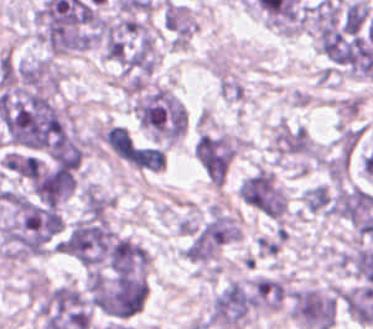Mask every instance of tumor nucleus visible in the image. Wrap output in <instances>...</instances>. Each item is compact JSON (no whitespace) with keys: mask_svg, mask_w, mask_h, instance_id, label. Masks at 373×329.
Returning a JSON list of instances; mask_svg holds the SVG:
<instances>
[{"mask_svg":"<svg viewBox=\"0 0 373 329\" xmlns=\"http://www.w3.org/2000/svg\"><path fill=\"white\" fill-rule=\"evenodd\" d=\"M232 238V217L224 211L211 210L186 230L183 258L197 264H211Z\"/></svg>","mask_w":373,"mask_h":329,"instance_id":"1","label":"tumor nucleus"},{"mask_svg":"<svg viewBox=\"0 0 373 329\" xmlns=\"http://www.w3.org/2000/svg\"><path fill=\"white\" fill-rule=\"evenodd\" d=\"M358 140V131L342 126L324 161L326 175L332 182H341L345 176Z\"/></svg>","mask_w":373,"mask_h":329,"instance_id":"2","label":"tumor nucleus"},{"mask_svg":"<svg viewBox=\"0 0 373 329\" xmlns=\"http://www.w3.org/2000/svg\"><path fill=\"white\" fill-rule=\"evenodd\" d=\"M273 151L278 156H312L313 143L302 126L278 123L272 132Z\"/></svg>","mask_w":373,"mask_h":329,"instance_id":"3","label":"tumor nucleus"},{"mask_svg":"<svg viewBox=\"0 0 373 329\" xmlns=\"http://www.w3.org/2000/svg\"><path fill=\"white\" fill-rule=\"evenodd\" d=\"M254 305L259 309L279 306L286 292L284 282L269 276H255L249 280Z\"/></svg>","mask_w":373,"mask_h":329,"instance_id":"4","label":"tumor nucleus"},{"mask_svg":"<svg viewBox=\"0 0 373 329\" xmlns=\"http://www.w3.org/2000/svg\"><path fill=\"white\" fill-rule=\"evenodd\" d=\"M111 205V197L93 184L82 188V210L89 216H105Z\"/></svg>","mask_w":373,"mask_h":329,"instance_id":"5","label":"tumor nucleus"},{"mask_svg":"<svg viewBox=\"0 0 373 329\" xmlns=\"http://www.w3.org/2000/svg\"><path fill=\"white\" fill-rule=\"evenodd\" d=\"M301 197L304 207L312 212L328 215L332 200L327 186L322 184L307 186Z\"/></svg>","mask_w":373,"mask_h":329,"instance_id":"6","label":"tumor nucleus"},{"mask_svg":"<svg viewBox=\"0 0 373 329\" xmlns=\"http://www.w3.org/2000/svg\"><path fill=\"white\" fill-rule=\"evenodd\" d=\"M281 242L274 236H260L254 248L260 256H274L280 249Z\"/></svg>","mask_w":373,"mask_h":329,"instance_id":"7","label":"tumor nucleus"}]
</instances>
